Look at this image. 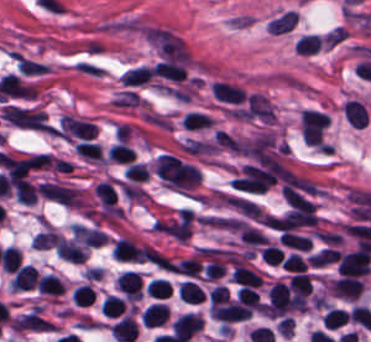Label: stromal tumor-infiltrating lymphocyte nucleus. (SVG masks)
I'll return each mask as SVG.
<instances>
[{
    "label": "stromal tumor-infiltrating lymphocyte nucleus",
    "mask_w": 371,
    "mask_h": 342,
    "mask_svg": "<svg viewBox=\"0 0 371 342\" xmlns=\"http://www.w3.org/2000/svg\"><path fill=\"white\" fill-rule=\"evenodd\" d=\"M152 247L126 236L116 238L113 253L119 260H146Z\"/></svg>",
    "instance_id": "bc302bb0"
},
{
    "label": "stromal tumor-infiltrating lymphocyte nucleus",
    "mask_w": 371,
    "mask_h": 342,
    "mask_svg": "<svg viewBox=\"0 0 371 342\" xmlns=\"http://www.w3.org/2000/svg\"><path fill=\"white\" fill-rule=\"evenodd\" d=\"M204 323L203 315L195 312H182L172 322V332L188 342Z\"/></svg>",
    "instance_id": "52c7bb5b"
},
{
    "label": "stromal tumor-infiltrating lymphocyte nucleus",
    "mask_w": 371,
    "mask_h": 342,
    "mask_svg": "<svg viewBox=\"0 0 371 342\" xmlns=\"http://www.w3.org/2000/svg\"><path fill=\"white\" fill-rule=\"evenodd\" d=\"M365 280L360 276L342 275L332 281L329 289L336 295L357 299L363 292Z\"/></svg>",
    "instance_id": "3290ff9b"
},
{
    "label": "stromal tumor-infiltrating lymphocyte nucleus",
    "mask_w": 371,
    "mask_h": 342,
    "mask_svg": "<svg viewBox=\"0 0 371 342\" xmlns=\"http://www.w3.org/2000/svg\"><path fill=\"white\" fill-rule=\"evenodd\" d=\"M213 93L222 100L233 103H242L246 99L242 85L224 79H217L213 83Z\"/></svg>",
    "instance_id": "abfb95fc"
},
{
    "label": "stromal tumor-infiltrating lymphocyte nucleus",
    "mask_w": 371,
    "mask_h": 342,
    "mask_svg": "<svg viewBox=\"0 0 371 342\" xmlns=\"http://www.w3.org/2000/svg\"><path fill=\"white\" fill-rule=\"evenodd\" d=\"M38 276L39 274L35 266L27 263L21 265L15 271L9 282L11 286L17 290L34 289L37 284Z\"/></svg>",
    "instance_id": "9ea309e8"
},
{
    "label": "stromal tumor-infiltrating lymphocyte nucleus",
    "mask_w": 371,
    "mask_h": 342,
    "mask_svg": "<svg viewBox=\"0 0 371 342\" xmlns=\"http://www.w3.org/2000/svg\"><path fill=\"white\" fill-rule=\"evenodd\" d=\"M110 331L117 342H134L137 322L132 315H125L111 327Z\"/></svg>",
    "instance_id": "f3e2335f"
},
{
    "label": "stromal tumor-infiltrating lymphocyte nucleus",
    "mask_w": 371,
    "mask_h": 342,
    "mask_svg": "<svg viewBox=\"0 0 371 342\" xmlns=\"http://www.w3.org/2000/svg\"><path fill=\"white\" fill-rule=\"evenodd\" d=\"M118 287L127 297L138 299L142 293V280L137 271L125 270L119 277Z\"/></svg>",
    "instance_id": "4f13568d"
},
{
    "label": "stromal tumor-infiltrating lymphocyte nucleus",
    "mask_w": 371,
    "mask_h": 342,
    "mask_svg": "<svg viewBox=\"0 0 371 342\" xmlns=\"http://www.w3.org/2000/svg\"><path fill=\"white\" fill-rule=\"evenodd\" d=\"M167 315V305L160 301H153L142 310L141 319L144 324L151 327L163 323Z\"/></svg>",
    "instance_id": "2a367800"
},
{
    "label": "stromal tumor-infiltrating lymphocyte nucleus",
    "mask_w": 371,
    "mask_h": 342,
    "mask_svg": "<svg viewBox=\"0 0 371 342\" xmlns=\"http://www.w3.org/2000/svg\"><path fill=\"white\" fill-rule=\"evenodd\" d=\"M39 291L48 294H61L65 291V283L58 274L45 272L39 276L37 283Z\"/></svg>",
    "instance_id": "4803ca6d"
},
{
    "label": "stromal tumor-infiltrating lymphocyte nucleus",
    "mask_w": 371,
    "mask_h": 342,
    "mask_svg": "<svg viewBox=\"0 0 371 342\" xmlns=\"http://www.w3.org/2000/svg\"><path fill=\"white\" fill-rule=\"evenodd\" d=\"M236 282L259 286L263 278L249 265L236 263L233 275L231 277Z\"/></svg>",
    "instance_id": "4245b91a"
},
{
    "label": "stromal tumor-infiltrating lymphocyte nucleus",
    "mask_w": 371,
    "mask_h": 342,
    "mask_svg": "<svg viewBox=\"0 0 371 342\" xmlns=\"http://www.w3.org/2000/svg\"><path fill=\"white\" fill-rule=\"evenodd\" d=\"M178 293L183 301L201 302L205 298L204 289L194 279L189 278L179 284Z\"/></svg>",
    "instance_id": "4c9ddf68"
},
{
    "label": "stromal tumor-infiltrating lymphocyte nucleus",
    "mask_w": 371,
    "mask_h": 342,
    "mask_svg": "<svg viewBox=\"0 0 371 342\" xmlns=\"http://www.w3.org/2000/svg\"><path fill=\"white\" fill-rule=\"evenodd\" d=\"M279 239L285 245L298 250H309L312 244L311 237L291 229H283Z\"/></svg>",
    "instance_id": "2761f720"
},
{
    "label": "stromal tumor-infiltrating lymphocyte nucleus",
    "mask_w": 371,
    "mask_h": 342,
    "mask_svg": "<svg viewBox=\"0 0 371 342\" xmlns=\"http://www.w3.org/2000/svg\"><path fill=\"white\" fill-rule=\"evenodd\" d=\"M239 301L249 310H262L263 307L259 291L250 284H243L240 288Z\"/></svg>",
    "instance_id": "3c572f05"
},
{
    "label": "stromal tumor-infiltrating lymphocyte nucleus",
    "mask_w": 371,
    "mask_h": 342,
    "mask_svg": "<svg viewBox=\"0 0 371 342\" xmlns=\"http://www.w3.org/2000/svg\"><path fill=\"white\" fill-rule=\"evenodd\" d=\"M152 75L153 70L151 66L141 64L122 73L121 80L126 85H136L148 81Z\"/></svg>",
    "instance_id": "42bb06b2"
},
{
    "label": "stromal tumor-infiltrating lymphocyte nucleus",
    "mask_w": 371,
    "mask_h": 342,
    "mask_svg": "<svg viewBox=\"0 0 371 342\" xmlns=\"http://www.w3.org/2000/svg\"><path fill=\"white\" fill-rule=\"evenodd\" d=\"M297 19L298 14L294 10H287L270 20L267 29L272 32H286L297 23Z\"/></svg>",
    "instance_id": "9e4306bb"
},
{
    "label": "stromal tumor-infiltrating lymphocyte nucleus",
    "mask_w": 371,
    "mask_h": 342,
    "mask_svg": "<svg viewBox=\"0 0 371 342\" xmlns=\"http://www.w3.org/2000/svg\"><path fill=\"white\" fill-rule=\"evenodd\" d=\"M213 119L210 114L205 113L201 110H188L184 116L182 123L184 126L191 129H199L208 127L213 123Z\"/></svg>",
    "instance_id": "04cf8593"
},
{
    "label": "stromal tumor-infiltrating lymphocyte nucleus",
    "mask_w": 371,
    "mask_h": 342,
    "mask_svg": "<svg viewBox=\"0 0 371 342\" xmlns=\"http://www.w3.org/2000/svg\"><path fill=\"white\" fill-rule=\"evenodd\" d=\"M95 193L100 203L106 208H113L117 192L110 180H102L94 185Z\"/></svg>",
    "instance_id": "e9af9c67"
},
{
    "label": "stromal tumor-infiltrating lymphocyte nucleus",
    "mask_w": 371,
    "mask_h": 342,
    "mask_svg": "<svg viewBox=\"0 0 371 342\" xmlns=\"http://www.w3.org/2000/svg\"><path fill=\"white\" fill-rule=\"evenodd\" d=\"M312 286V275L303 271H296L290 279V287L297 296H308Z\"/></svg>",
    "instance_id": "782c7336"
},
{
    "label": "stromal tumor-infiltrating lymphocyte nucleus",
    "mask_w": 371,
    "mask_h": 342,
    "mask_svg": "<svg viewBox=\"0 0 371 342\" xmlns=\"http://www.w3.org/2000/svg\"><path fill=\"white\" fill-rule=\"evenodd\" d=\"M107 155L111 161L124 163H132L136 156L134 149L121 141L109 147Z\"/></svg>",
    "instance_id": "cac63f63"
},
{
    "label": "stromal tumor-infiltrating lymphocyte nucleus",
    "mask_w": 371,
    "mask_h": 342,
    "mask_svg": "<svg viewBox=\"0 0 371 342\" xmlns=\"http://www.w3.org/2000/svg\"><path fill=\"white\" fill-rule=\"evenodd\" d=\"M61 234L51 228H46L35 234L32 243L37 249H48L55 246Z\"/></svg>",
    "instance_id": "2e467ee5"
},
{
    "label": "stromal tumor-infiltrating lymphocyte nucleus",
    "mask_w": 371,
    "mask_h": 342,
    "mask_svg": "<svg viewBox=\"0 0 371 342\" xmlns=\"http://www.w3.org/2000/svg\"><path fill=\"white\" fill-rule=\"evenodd\" d=\"M323 43V37L318 33H305L297 42L296 50L302 53H315Z\"/></svg>",
    "instance_id": "7eef579d"
},
{
    "label": "stromal tumor-infiltrating lymphocyte nucleus",
    "mask_w": 371,
    "mask_h": 342,
    "mask_svg": "<svg viewBox=\"0 0 371 342\" xmlns=\"http://www.w3.org/2000/svg\"><path fill=\"white\" fill-rule=\"evenodd\" d=\"M106 316H117L125 307V300L113 295L106 294L99 305Z\"/></svg>",
    "instance_id": "c26a33f6"
},
{
    "label": "stromal tumor-infiltrating lymphocyte nucleus",
    "mask_w": 371,
    "mask_h": 342,
    "mask_svg": "<svg viewBox=\"0 0 371 342\" xmlns=\"http://www.w3.org/2000/svg\"><path fill=\"white\" fill-rule=\"evenodd\" d=\"M349 315L344 307H331L323 316L327 328H336L345 325Z\"/></svg>",
    "instance_id": "3e0999b9"
},
{
    "label": "stromal tumor-infiltrating lymphocyte nucleus",
    "mask_w": 371,
    "mask_h": 342,
    "mask_svg": "<svg viewBox=\"0 0 371 342\" xmlns=\"http://www.w3.org/2000/svg\"><path fill=\"white\" fill-rule=\"evenodd\" d=\"M96 290L89 283H81L73 292V298L78 305H90L95 300Z\"/></svg>",
    "instance_id": "a0a3295f"
},
{
    "label": "stromal tumor-infiltrating lymphocyte nucleus",
    "mask_w": 371,
    "mask_h": 342,
    "mask_svg": "<svg viewBox=\"0 0 371 342\" xmlns=\"http://www.w3.org/2000/svg\"><path fill=\"white\" fill-rule=\"evenodd\" d=\"M282 266L291 270L303 271L307 269L308 262L301 255L292 252L283 259Z\"/></svg>",
    "instance_id": "b6af03f8"
}]
</instances>
